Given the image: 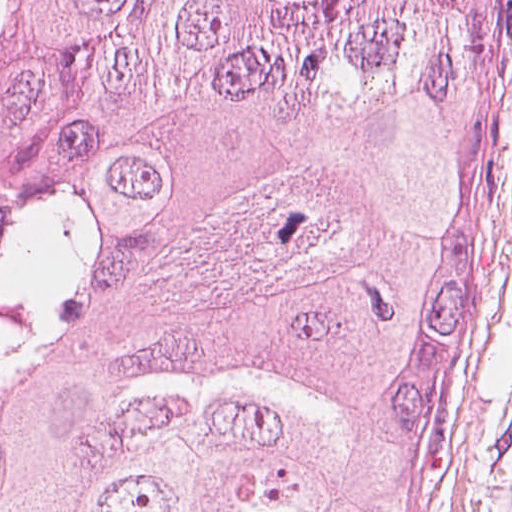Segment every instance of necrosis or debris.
Instances as JSON below:
<instances>
[{
  "label": "necrosis or debris",
  "instance_id": "1",
  "mask_svg": "<svg viewBox=\"0 0 512 512\" xmlns=\"http://www.w3.org/2000/svg\"><path fill=\"white\" fill-rule=\"evenodd\" d=\"M15 263V244L0 230V345L15 336L19 318L18 296L10 280Z\"/></svg>",
  "mask_w": 512,
  "mask_h": 512
}]
</instances>
